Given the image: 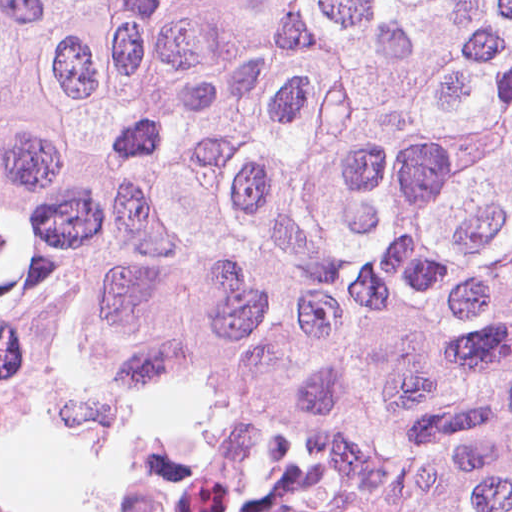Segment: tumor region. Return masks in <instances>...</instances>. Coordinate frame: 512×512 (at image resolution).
<instances>
[{
	"label": "tumor region",
	"instance_id": "tumor-region-1",
	"mask_svg": "<svg viewBox=\"0 0 512 512\" xmlns=\"http://www.w3.org/2000/svg\"><path fill=\"white\" fill-rule=\"evenodd\" d=\"M0 379L165 512H512V0H0Z\"/></svg>",
	"mask_w": 512,
	"mask_h": 512
}]
</instances>
